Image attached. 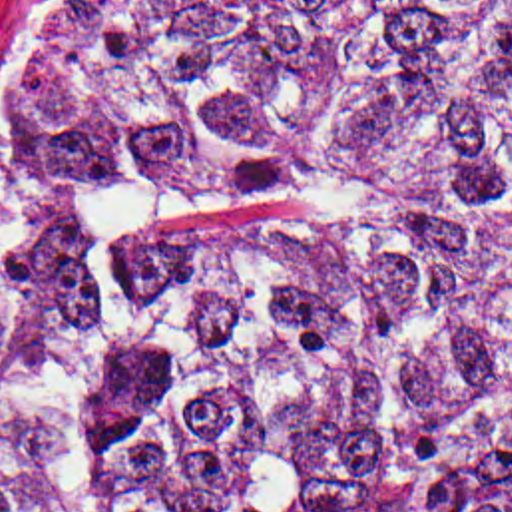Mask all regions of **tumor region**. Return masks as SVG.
<instances>
[{
	"mask_svg": "<svg viewBox=\"0 0 512 512\" xmlns=\"http://www.w3.org/2000/svg\"><path fill=\"white\" fill-rule=\"evenodd\" d=\"M0 512H512V0H165L50 115Z\"/></svg>",
	"mask_w": 512,
	"mask_h": 512,
	"instance_id": "1",
	"label": "tumor region"
}]
</instances>
